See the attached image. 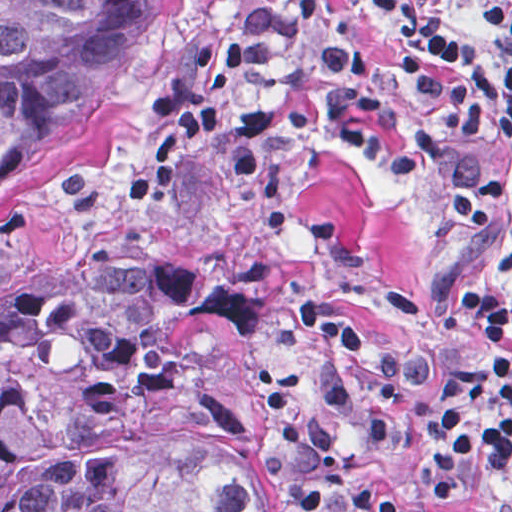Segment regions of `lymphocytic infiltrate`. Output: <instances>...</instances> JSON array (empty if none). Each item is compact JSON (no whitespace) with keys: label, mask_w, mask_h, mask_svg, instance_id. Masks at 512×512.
Segmentation results:
<instances>
[{"label":"lymphocytic infiltrate","mask_w":512,"mask_h":512,"mask_svg":"<svg viewBox=\"0 0 512 512\" xmlns=\"http://www.w3.org/2000/svg\"><path fill=\"white\" fill-rule=\"evenodd\" d=\"M396 26L388 57L364 55L340 0H254L234 60L294 67L320 56L321 97L249 112L241 134L330 129L390 168L412 171L477 145H512V7L494 4L483 32L465 36L419 0H379ZM512 197V168L448 189L433 208L469 230H488L482 206ZM512 231V218L510 219ZM357 305L397 338L349 285ZM444 293L512 351V282L444 269ZM294 322L325 349L313 382L273 394L275 426L310 512H467L430 509L480 452V427L501 462L512 512V366L471 348H419L397 340L441 385L426 406L423 485L392 488L365 467L393 423L403 365L372 342L344 304L302 287Z\"/></svg>","instance_id":"lymphocytic-infiltrate-1"}]
</instances>
